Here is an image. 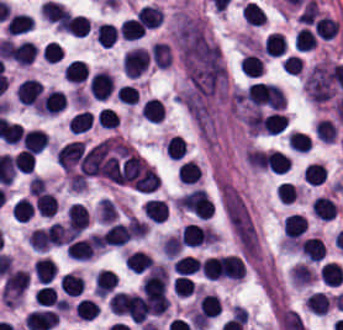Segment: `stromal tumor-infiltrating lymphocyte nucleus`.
<instances>
[{"label":"stromal tumor-infiltrating lymphocyte nucleus","instance_id":"83f04bf1","mask_svg":"<svg viewBox=\"0 0 343 330\" xmlns=\"http://www.w3.org/2000/svg\"><path fill=\"white\" fill-rule=\"evenodd\" d=\"M13 168L16 172L29 173L35 165V157L29 151L20 149L18 153L11 159Z\"/></svg>","mask_w":343,"mask_h":330},{"label":"stromal tumor-infiltrating lymphocyte nucleus","instance_id":"e9af9c67","mask_svg":"<svg viewBox=\"0 0 343 330\" xmlns=\"http://www.w3.org/2000/svg\"><path fill=\"white\" fill-rule=\"evenodd\" d=\"M48 137L43 130L31 129L24 133L21 146L30 152H39L47 146Z\"/></svg>","mask_w":343,"mask_h":330},{"label":"stromal tumor-infiltrating lymphocyte nucleus","instance_id":"6c763739","mask_svg":"<svg viewBox=\"0 0 343 330\" xmlns=\"http://www.w3.org/2000/svg\"><path fill=\"white\" fill-rule=\"evenodd\" d=\"M34 207L43 217L49 218L57 212L56 196L43 190L36 196Z\"/></svg>","mask_w":343,"mask_h":330},{"label":"stromal tumor-infiltrating lymphocyte nucleus","instance_id":"42bb06b2","mask_svg":"<svg viewBox=\"0 0 343 330\" xmlns=\"http://www.w3.org/2000/svg\"><path fill=\"white\" fill-rule=\"evenodd\" d=\"M58 30L73 36H85L90 30L89 18L71 14Z\"/></svg>","mask_w":343,"mask_h":330},{"label":"stromal tumor-infiltrating lymphocyte nucleus","instance_id":"c26a33f6","mask_svg":"<svg viewBox=\"0 0 343 330\" xmlns=\"http://www.w3.org/2000/svg\"><path fill=\"white\" fill-rule=\"evenodd\" d=\"M319 273L328 286H339L343 283V268L338 262H325Z\"/></svg>","mask_w":343,"mask_h":330},{"label":"stromal tumor-infiltrating lymphocyte nucleus","instance_id":"4f13568d","mask_svg":"<svg viewBox=\"0 0 343 330\" xmlns=\"http://www.w3.org/2000/svg\"><path fill=\"white\" fill-rule=\"evenodd\" d=\"M288 119L283 111H269L261 117V128L264 133L278 135L287 125Z\"/></svg>","mask_w":343,"mask_h":330},{"label":"stromal tumor-infiltrating lymphocyte nucleus","instance_id":"023d44f5","mask_svg":"<svg viewBox=\"0 0 343 330\" xmlns=\"http://www.w3.org/2000/svg\"><path fill=\"white\" fill-rule=\"evenodd\" d=\"M314 133L320 141L331 143L337 136V129L331 119L321 117L314 124Z\"/></svg>","mask_w":343,"mask_h":330},{"label":"stromal tumor-infiltrating lymphocyte nucleus","instance_id":"782c7336","mask_svg":"<svg viewBox=\"0 0 343 330\" xmlns=\"http://www.w3.org/2000/svg\"><path fill=\"white\" fill-rule=\"evenodd\" d=\"M336 204L325 195H317L312 199V212L320 220H329L335 213Z\"/></svg>","mask_w":343,"mask_h":330},{"label":"stromal tumor-infiltrating lymphocyte nucleus","instance_id":"9e4306bb","mask_svg":"<svg viewBox=\"0 0 343 330\" xmlns=\"http://www.w3.org/2000/svg\"><path fill=\"white\" fill-rule=\"evenodd\" d=\"M221 302L216 295H203L198 304V317L201 320H211L220 315Z\"/></svg>","mask_w":343,"mask_h":330},{"label":"stromal tumor-infiltrating lymphocyte nucleus","instance_id":"3e0999b9","mask_svg":"<svg viewBox=\"0 0 343 330\" xmlns=\"http://www.w3.org/2000/svg\"><path fill=\"white\" fill-rule=\"evenodd\" d=\"M150 57L153 65L160 68L169 67L172 55L168 43L156 42L150 46Z\"/></svg>","mask_w":343,"mask_h":330},{"label":"stromal tumor-infiltrating lymphocyte nucleus","instance_id":"21d57d70","mask_svg":"<svg viewBox=\"0 0 343 330\" xmlns=\"http://www.w3.org/2000/svg\"><path fill=\"white\" fill-rule=\"evenodd\" d=\"M33 25V21L26 14L15 13L8 18L6 35H20Z\"/></svg>","mask_w":343,"mask_h":330},{"label":"stromal tumor-infiltrating lymphocyte nucleus","instance_id":"02f42fee","mask_svg":"<svg viewBox=\"0 0 343 330\" xmlns=\"http://www.w3.org/2000/svg\"><path fill=\"white\" fill-rule=\"evenodd\" d=\"M66 80L74 83L85 81L89 69L85 62L80 59H73L63 70Z\"/></svg>","mask_w":343,"mask_h":330},{"label":"stromal tumor-infiltrating lymphocyte nucleus","instance_id":"1d375fb5","mask_svg":"<svg viewBox=\"0 0 343 330\" xmlns=\"http://www.w3.org/2000/svg\"><path fill=\"white\" fill-rule=\"evenodd\" d=\"M142 116L146 121L158 122L163 117V103L160 99L149 97L142 105Z\"/></svg>","mask_w":343,"mask_h":330},{"label":"stromal tumor-infiltrating lymphocyte nucleus","instance_id":"fc20714e","mask_svg":"<svg viewBox=\"0 0 343 330\" xmlns=\"http://www.w3.org/2000/svg\"><path fill=\"white\" fill-rule=\"evenodd\" d=\"M302 61L300 57H297L293 54H288L283 57L280 62V69L285 74H299Z\"/></svg>","mask_w":343,"mask_h":330},{"label":"stromal tumor-infiltrating lymphocyte nucleus","instance_id":"bc302bb0","mask_svg":"<svg viewBox=\"0 0 343 330\" xmlns=\"http://www.w3.org/2000/svg\"><path fill=\"white\" fill-rule=\"evenodd\" d=\"M147 63V48L135 46L122 56L121 68L129 77L136 78L147 68Z\"/></svg>","mask_w":343,"mask_h":330},{"label":"stromal tumor-infiltrating lymphocyte nucleus","instance_id":"2761f720","mask_svg":"<svg viewBox=\"0 0 343 330\" xmlns=\"http://www.w3.org/2000/svg\"><path fill=\"white\" fill-rule=\"evenodd\" d=\"M36 305L62 310V300L51 284H43L34 293Z\"/></svg>","mask_w":343,"mask_h":330},{"label":"stromal tumor-infiltrating lymphocyte nucleus","instance_id":"a33fdf23","mask_svg":"<svg viewBox=\"0 0 343 330\" xmlns=\"http://www.w3.org/2000/svg\"><path fill=\"white\" fill-rule=\"evenodd\" d=\"M241 72L249 77H257L263 73L262 59L254 53H247L241 61Z\"/></svg>","mask_w":343,"mask_h":330},{"label":"stromal tumor-infiltrating lymphocyte nucleus","instance_id":"a6e9041d","mask_svg":"<svg viewBox=\"0 0 343 330\" xmlns=\"http://www.w3.org/2000/svg\"><path fill=\"white\" fill-rule=\"evenodd\" d=\"M305 181L309 185H319L326 179V168L321 162L306 164L304 168Z\"/></svg>","mask_w":343,"mask_h":330},{"label":"stromal tumor-infiltrating lymphocyte nucleus","instance_id":"c8d0df70","mask_svg":"<svg viewBox=\"0 0 343 330\" xmlns=\"http://www.w3.org/2000/svg\"><path fill=\"white\" fill-rule=\"evenodd\" d=\"M125 41H132L143 36L144 29L140 23L131 16L122 20L119 28Z\"/></svg>","mask_w":343,"mask_h":330},{"label":"stromal tumor-infiltrating lymphocyte nucleus","instance_id":"84afeb40","mask_svg":"<svg viewBox=\"0 0 343 330\" xmlns=\"http://www.w3.org/2000/svg\"><path fill=\"white\" fill-rule=\"evenodd\" d=\"M83 279L78 273L66 272L61 277V290L69 296H77L82 289Z\"/></svg>","mask_w":343,"mask_h":330},{"label":"stromal tumor-infiltrating lymphocyte nucleus","instance_id":"ccc9de39","mask_svg":"<svg viewBox=\"0 0 343 330\" xmlns=\"http://www.w3.org/2000/svg\"><path fill=\"white\" fill-rule=\"evenodd\" d=\"M11 212L15 221L27 222L33 214V206L30 200L22 196L13 204Z\"/></svg>","mask_w":343,"mask_h":330},{"label":"stromal tumor-infiltrating lymphocyte nucleus","instance_id":"b6af03f8","mask_svg":"<svg viewBox=\"0 0 343 330\" xmlns=\"http://www.w3.org/2000/svg\"><path fill=\"white\" fill-rule=\"evenodd\" d=\"M201 176V169L192 159H185L178 167V180L182 184H195Z\"/></svg>","mask_w":343,"mask_h":330},{"label":"stromal tumor-infiltrating lymphocyte nucleus","instance_id":"cac63f63","mask_svg":"<svg viewBox=\"0 0 343 330\" xmlns=\"http://www.w3.org/2000/svg\"><path fill=\"white\" fill-rule=\"evenodd\" d=\"M284 51V35L278 31H270L263 41L262 53L270 57H279Z\"/></svg>","mask_w":343,"mask_h":330},{"label":"stromal tumor-infiltrating lymphocyte nucleus","instance_id":"2e467ee5","mask_svg":"<svg viewBox=\"0 0 343 330\" xmlns=\"http://www.w3.org/2000/svg\"><path fill=\"white\" fill-rule=\"evenodd\" d=\"M263 159L269 171L273 173H286L290 163L289 156L273 148L263 156Z\"/></svg>","mask_w":343,"mask_h":330},{"label":"stromal tumor-infiltrating lymphocyte nucleus","instance_id":"52c7bb5b","mask_svg":"<svg viewBox=\"0 0 343 330\" xmlns=\"http://www.w3.org/2000/svg\"><path fill=\"white\" fill-rule=\"evenodd\" d=\"M131 236V220L117 222L109 226L100 235V242L104 247H122Z\"/></svg>","mask_w":343,"mask_h":330},{"label":"stromal tumor-infiltrating lymphocyte nucleus","instance_id":"a0a3295f","mask_svg":"<svg viewBox=\"0 0 343 330\" xmlns=\"http://www.w3.org/2000/svg\"><path fill=\"white\" fill-rule=\"evenodd\" d=\"M331 299L325 293L312 291L305 299V307L316 315H325Z\"/></svg>","mask_w":343,"mask_h":330},{"label":"stromal tumor-infiltrating lymphocyte nucleus","instance_id":"9ea309e8","mask_svg":"<svg viewBox=\"0 0 343 330\" xmlns=\"http://www.w3.org/2000/svg\"><path fill=\"white\" fill-rule=\"evenodd\" d=\"M20 104L37 106L41 101L42 87L37 79L25 78L15 92Z\"/></svg>","mask_w":343,"mask_h":330},{"label":"stromal tumor-infiltrating lymphocyte nucleus","instance_id":"2a367800","mask_svg":"<svg viewBox=\"0 0 343 330\" xmlns=\"http://www.w3.org/2000/svg\"><path fill=\"white\" fill-rule=\"evenodd\" d=\"M307 230V219L297 214L285 217L283 233L285 239L297 241Z\"/></svg>","mask_w":343,"mask_h":330},{"label":"stromal tumor-infiltrating lymphocyte nucleus","instance_id":"18da8d3c","mask_svg":"<svg viewBox=\"0 0 343 330\" xmlns=\"http://www.w3.org/2000/svg\"><path fill=\"white\" fill-rule=\"evenodd\" d=\"M94 116L91 111L79 110L67 122L69 132L80 133L91 127Z\"/></svg>","mask_w":343,"mask_h":330},{"label":"stromal tumor-infiltrating lymphocyte nucleus","instance_id":"afbf053c","mask_svg":"<svg viewBox=\"0 0 343 330\" xmlns=\"http://www.w3.org/2000/svg\"><path fill=\"white\" fill-rule=\"evenodd\" d=\"M117 27L114 24L107 22H100L94 32L95 41L101 47H110L115 41Z\"/></svg>","mask_w":343,"mask_h":330},{"label":"stromal tumor-infiltrating lymphocyte nucleus","instance_id":"7eef579d","mask_svg":"<svg viewBox=\"0 0 343 330\" xmlns=\"http://www.w3.org/2000/svg\"><path fill=\"white\" fill-rule=\"evenodd\" d=\"M242 20L251 26H262L265 22L264 11L258 3L245 1L241 6Z\"/></svg>","mask_w":343,"mask_h":330},{"label":"stromal tumor-infiltrating lymphocyte nucleus","instance_id":"abfb95fc","mask_svg":"<svg viewBox=\"0 0 343 330\" xmlns=\"http://www.w3.org/2000/svg\"><path fill=\"white\" fill-rule=\"evenodd\" d=\"M114 83L108 71L98 69L89 76L88 93L93 95L98 100H105L110 94Z\"/></svg>","mask_w":343,"mask_h":330},{"label":"stromal tumor-infiltrating lymphocyte nucleus","instance_id":"3c572f05","mask_svg":"<svg viewBox=\"0 0 343 330\" xmlns=\"http://www.w3.org/2000/svg\"><path fill=\"white\" fill-rule=\"evenodd\" d=\"M136 17L146 28H155L163 19V12L158 5L142 4L136 10Z\"/></svg>","mask_w":343,"mask_h":330},{"label":"stromal tumor-infiltrating lymphocyte nucleus","instance_id":"04cf8593","mask_svg":"<svg viewBox=\"0 0 343 330\" xmlns=\"http://www.w3.org/2000/svg\"><path fill=\"white\" fill-rule=\"evenodd\" d=\"M52 227L44 226L31 230L29 244L32 250L44 252L51 246Z\"/></svg>","mask_w":343,"mask_h":330},{"label":"stromal tumor-infiltrating lymphocyte nucleus","instance_id":"16295066","mask_svg":"<svg viewBox=\"0 0 343 330\" xmlns=\"http://www.w3.org/2000/svg\"><path fill=\"white\" fill-rule=\"evenodd\" d=\"M172 269L179 275H189L200 269V262L191 256L183 255L176 259Z\"/></svg>","mask_w":343,"mask_h":330},{"label":"stromal tumor-infiltrating lymphocyte nucleus","instance_id":"8379cbfb","mask_svg":"<svg viewBox=\"0 0 343 330\" xmlns=\"http://www.w3.org/2000/svg\"><path fill=\"white\" fill-rule=\"evenodd\" d=\"M74 313L82 320H94L100 313V306L93 299H79L74 306Z\"/></svg>","mask_w":343,"mask_h":330},{"label":"stromal tumor-infiltrating lymphocyte nucleus","instance_id":"4245b91a","mask_svg":"<svg viewBox=\"0 0 343 330\" xmlns=\"http://www.w3.org/2000/svg\"><path fill=\"white\" fill-rule=\"evenodd\" d=\"M32 272L38 284H48L56 275L51 258L40 257L32 264Z\"/></svg>","mask_w":343,"mask_h":330},{"label":"stromal tumor-infiltrating lymphocyte nucleus","instance_id":"50b3126c","mask_svg":"<svg viewBox=\"0 0 343 330\" xmlns=\"http://www.w3.org/2000/svg\"><path fill=\"white\" fill-rule=\"evenodd\" d=\"M117 121V114L109 106H101L95 119L97 125L103 128H115Z\"/></svg>","mask_w":343,"mask_h":330},{"label":"stromal tumor-infiltrating lymphocyte nucleus","instance_id":"f3e2335f","mask_svg":"<svg viewBox=\"0 0 343 330\" xmlns=\"http://www.w3.org/2000/svg\"><path fill=\"white\" fill-rule=\"evenodd\" d=\"M89 224L88 209L80 203H73L66 211V225L72 232H80Z\"/></svg>","mask_w":343,"mask_h":330},{"label":"stromal tumor-infiltrating lymphocyte nucleus","instance_id":"7b516f1d","mask_svg":"<svg viewBox=\"0 0 343 330\" xmlns=\"http://www.w3.org/2000/svg\"><path fill=\"white\" fill-rule=\"evenodd\" d=\"M164 149L167 157L180 159L186 150V141L179 135H172L164 143Z\"/></svg>","mask_w":343,"mask_h":330},{"label":"stromal tumor-infiltrating lymphocyte nucleus","instance_id":"4c9ddf68","mask_svg":"<svg viewBox=\"0 0 343 330\" xmlns=\"http://www.w3.org/2000/svg\"><path fill=\"white\" fill-rule=\"evenodd\" d=\"M124 262L127 270L141 274L154 264L151 257L136 249L126 253Z\"/></svg>","mask_w":343,"mask_h":330},{"label":"stromal tumor-infiltrating lymphocyte nucleus","instance_id":"6da75f8f","mask_svg":"<svg viewBox=\"0 0 343 330\" xmlns=\"http://www.w3.org/2000/svg\"><path fill=\"white\" fill-rule=\"evenodd\" d=\"M119 101L127 105H135L138 101V92L133 85L121 84L115 92Z\"/></svg>","mask_w":343,"mask_h":330},{"label":"stromal tumor-infiltrating lymphocyte nucleus","instance_id":"fa64b396","mask_svg":"<svg viewBox=\"0 0 343 330\" xmlns=\"http://www.w3.org/2000/svg\"><path fill=\"white\" fill-rule=\"evenodd\" d=\"M141 209L151 221L157 223L164 221L168 213L164 201L159 199H146Z\"/></svg>","mask_w":343,"mask_h":330},{"label":"stromal tumor-infiltrating lymphocyte nucleus","instance_id":"3290ff9b","mask_svg":"<svg viewBox=\"0 0 343 330\" xmlns=\"http://www.w3.org/2000/svg\"><path fill=\"white\" fill-rule=\"evenodd\" d=\"M11 60L20 66L30 64L35 59V46L27 39L10 40L6 43Z\"/></svg>","mask_w":343,"mask_h":330},{"label":"stromal tumor-infiltrating lymphocyte nucleus","instance_id":"4803ca6d","mask_svg":"<svg viewBox=\"0 0 343 330\" xmlns=\"http://www.w3.org/2000/svg\"><path fill=\"white\" fill-rule=\"evenodd\" d=\"M298 246L307 262H318L326 252L318 237H305Z\"/></svg>","mask_w":343,"mask_h":330}]
</instances>
